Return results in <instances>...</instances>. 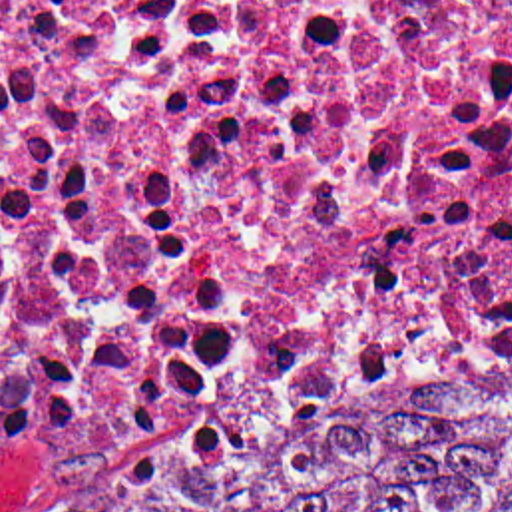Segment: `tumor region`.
<instances>
[{"label": "tumor region", "mask_w": 512, "mask_h": 512, "mask_svg": "<svg viewBox=\"0 0 512 512\" xmlns=\"http://www.w3.org/2000/svg\"><path fill=\"white\" fill-rule=\"evenodd\" d=\"M165 512H512V362L253 442Z\"/></svg>", "instance_id": "1"}]
</instances>
